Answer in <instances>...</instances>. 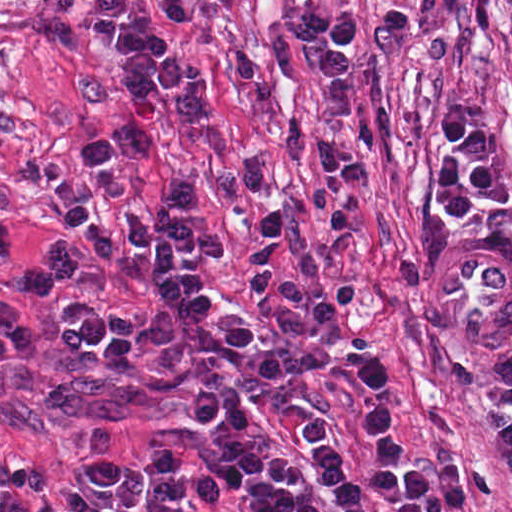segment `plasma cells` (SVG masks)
<instances>
[{
  "mask_svg": "<svg viewBox=\"0 0 512 512\" xmlns=\"http://www.w3.org/2000/svg\"><path fill=\"white\" fill-rule=\"evenodd\" d=\"M499 154L494 128L480 106L466 100L445 108L436 121L428 181L436 215L466 217L476 208V196L508 206V191L498 176ZM199 199L196 189L179 179L148 220L124 208L122 229L59 238L33 253L23 248L0 195V268L25 293L64 297L56 306V338L45 342L30 336L16 306L0 300V373L37 371L82 359L111 379L141 371L160 380L182 375L189 387L191 424L213 429L214 440L196 460L235 489L245 512H329L281 448L240 441L256 432L257 418L248 394L233 382L227 358L236 356L238 371L261 390L282 388L285 363L275 350H258L257 337L240 317L216 323L213 304L203 297L197 278L186 272L184 264L190 259L217 262L229 249L218 234L192 225L189 215ZM135 243L150 247L155 255L148 280L162 314L139 317L108 309L77 291L82 275L102 267L142 281L145 273L133 253ZM343 383L356 408L350 390L366 411L374 455L366 465L367 480L389 498L394 512H412L410 490L422 473L393 433L385 363L362 351ZM485 417L493 456L512 477V394L495 402ZM302 428L312 472L343 512H365L364 494L342 474V442L314 419L301 423V435ZM88 462L99 489L62 490L70 506L66 512H119L135 506L149 473L123 459L109 426L92 425ZM52 483L47 463L0 443V512H63L47 496L43 500Z\"/></svg>",
  "mask_w": 512,
  "mask_h": 512,
  "instance_id": "obj_1",
  "label": "plasma cells"
}]
</instances>
